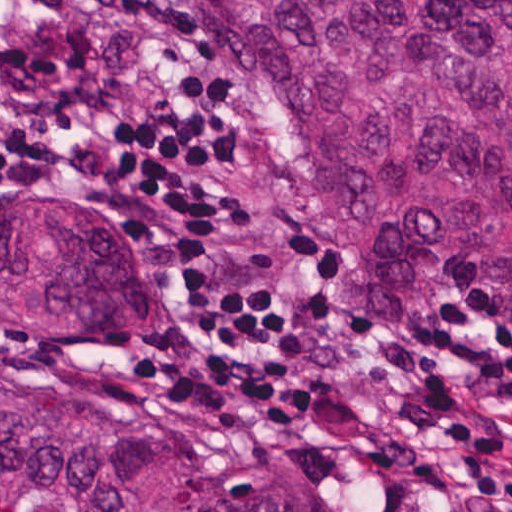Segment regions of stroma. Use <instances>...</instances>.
<instances>
[{"label":"stroma","mask_w":512,"mask_h":512,"mask_svg":"<svg viewBox=\"0 0 512 512\" xmlns=\"http://www.w3.org/2000/svg\"><path fill=\"white\" fill-rule=\"evenodd\" d=\"M150 22L178 63L222 82L241 136V178L253 227L269 242L295 246L321 289V342L295 368L249 395L149 397L138 363L175 343L192 298L177 284L151 232L127 213L19 175H0V208H76L139 243L156 261L174 297L158 317H68L0 307L37 366L52 377L151 415L210 460L278 475L315 512H463L469 483L452 451L426 435L433 467L456 497L433 502L388 481L363 452L368 432L404 424L409 394L378 369L375 346L411 347L433 318L466 306L505 279L512 266L466 284L417 312H377L362 305L327 237L322 212L302 173L284 159L265 118L224 58L205 47L173 0H150Z\"/></svg>","instance_id":"obj_1"}]
</instances>
